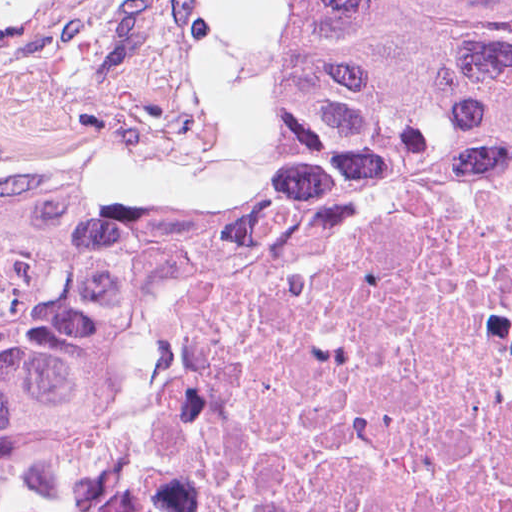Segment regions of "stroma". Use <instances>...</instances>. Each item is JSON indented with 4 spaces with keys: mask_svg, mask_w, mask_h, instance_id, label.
<instances>
[{
    "mask_svg": "<svg viewBox=\"0 0 512 512\" xmlns=\"http://www.w3.org/2000/svg\"><path fill=\"white\" fill-rule=\"evenodd\" d=\"M201 4L0 0V252L81 230L117 205L193 198L255 163L171 193H110L99 181L167 146L177 130L194 87ZM294 36L295 28L258 160L276 140L274 106Z\"/></svg>",
    "mask_w": 512,
    "mask_h": 512,
    "instance_id": "obj_1",
    "label": "stroma"
}]
</instances>
